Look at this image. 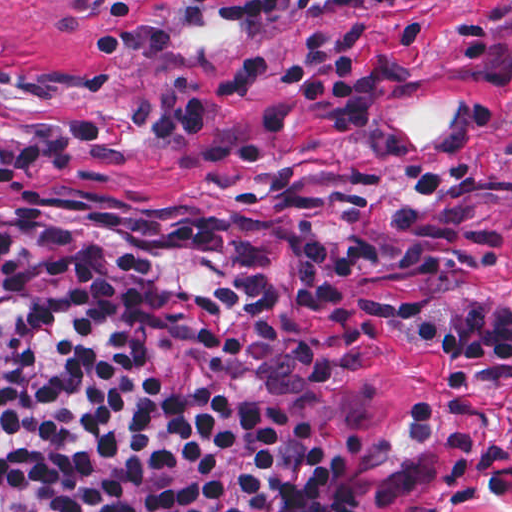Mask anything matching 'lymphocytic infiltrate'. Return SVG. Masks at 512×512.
Returning a JSON list of instances; mask_svg holds the SVG:
<instances>
[{"mask_svg": "<svg viewBox=\"0 0 512 512\" xmlns=\"http://www.w3.org/2000/svg\"><path fill=\"white\" fill-rule=\"evenodd\" d=\"M421 0H221V25L270 29L337 9ZM369 23L311 30L303 54L249 51L228 69H177L127 106L40 120L0 144V187L86 154L103 130L186 137L240 167L272 153L206 127L200 98L294 90L259 114L270 132L306 110L331 136L368 132L383 82ZM441 359L422 425L457 448L512 432V308L372 306L348 259L268 215H212L101 194L0 197V512H367L368 432L330 438L355 381L352 328Z\"/></svg>", "mask_w": 512, "mask_h": 512, "instance_id": "f902f5d3", "label": "lymphocytic infiltrate"}]
</instances>
